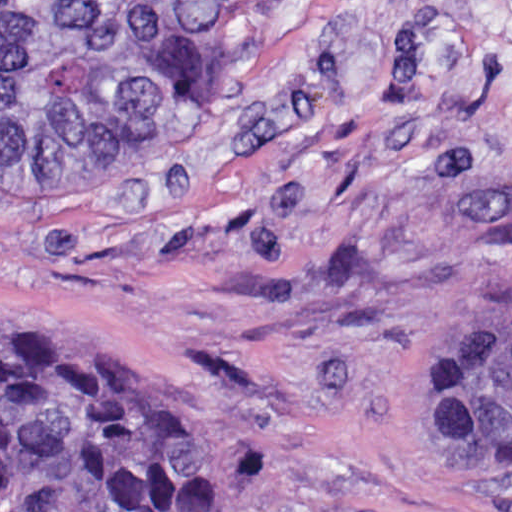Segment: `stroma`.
Instances as JSON below:
<instances>
[{"label": "stroma", "mask_w": 512, "mask_h": 512, "mask_svg": "<svg viewBox=\"0 0 512 512\" xmlns=\"http://www.w3.org/2000/svg\"><path fill=\"white\" fill-rule=\"evenodd\" d=\"M494 310L512 0H318L154 144L0 163V315L174 377L223 512H512V463L433 435L419 392L437 339Z\"/></svg>", "instance_id": "35a3bbf8"}]
</instances>
